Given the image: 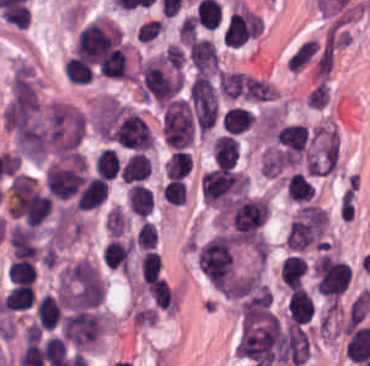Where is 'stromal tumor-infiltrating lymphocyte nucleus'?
<instances>
[{
    "label": "stromal tumor-infiltrating lymphocyte nucleus",
    "mask_w": 370,
    "mask_h": 366,
    "mask_svg": "<svg viewBox=\"0 0 370 366\" xmlns=\"http://www.w3.org/2000/svg\"><path fill=\"white\" fill-rule=\"evenodd\" d=\"M195 258L204 276H233L234 242L221 231L196 247Z\"/></svg>",
    "instance_id": "1"
},
{
    "label": "stromal tumor-infiltrating lymphocyte nucleus",
    "mask_w": 370,
    "mask_h": 366,
    "mask_svg": "<svg viewBox=\"0 0 370 366\" xmlns=\"http://www.w3.org/2000/svg\"><path fill=\"white\" fill-rule=\"evenodd\" d=\"M162 135L170 148L184 149L193 139V119L187 100L175 97L163 109Z\"/></svg>",
    "instance_id": "2"
},
{
    "label": "stromal tumor-infiltrating lymphocyte nucleus",
    "mask_w": 370,
    "mask_h": 366,
    "mask_svg": "<svg viewBox=\"0 0 370 366\" xmlns=\"http://www.w3.org/2000/svg\"><path fill=\"white\" fill-rule=\"evenodd\" d=\"M189 56L195 70L200 73H214L219 59L216 48L207 38L195 37L189 45Z\"/></svg>",
    "instance_id": "3"
},
{
    "label": "stromal tumor-infiltrating lymphocyte nucleus",
    "mask_w": 370,
    "mask_h": 366,
    "mask_svg": "<svg viewBox=\"0 0 370 366\" xmlns=\"http://www.w3.org/2000/svg\"><path fill=\"white\" fill-rule=\"evenodd\" d=\"M289 323H308L314 314L311 295L302 287H295L287 302Z\"/></svg>",
    "instance_id": "4"
},
{
    "label": "stromal tumor-infiltrating lymphocyte nucleus",
    "mask_w": 370,
    "mask_h": 366,
    "mask_svg": "<svg viewBox=\"0 0 370 366\" xmlns=\"http://www.w3.org/2000/svg\"><path fill=\"white\" fill-rule=\"evenodd\" d=\"M107 179L90 176L78 191L77 209L90 210L105 200Z\"/></svg>",
    "instance_id": "5"
},
{
    "label": "stromal tumor-infiltrating lymphocyte nucleus",
    "mask_w": 370,
    "mask_h": 366,
    "mask_svg": "<svg viewBox=\"0 0 370 366\" xmlns=\"http://www.w3.org/2000/svg\"><path fill=\"white\" fill-rule=\"evenodd\" d=\"M242 100L248 103H272L276 101L275 86L265 78L247 73Z\"/></svg>",
    "instance_id": "6"
},
{
    "label": "stromal tumor-infiltrating lymphocyte nucleus",
    "mask_w": 370,
    "mask_h": 366,
    "mask_svg": "<svg viewBox=\"0 0 370 366\" xmlns=\"http://www.w3.org/2000/svg\"><path fill=\"white\" fill-rule=\"evenodd\" d=\"M212 154L216 165H235L239 157V145L233 134H220L212 143Z\"/></svg>",
    "instance_id": "7"
},
{
    "label": "stromal tumor-infiltrating lymphocyte nucleus",
    "mask_w": 370,
    "mask_h": 366,
    "mask_svg": "<svg viewBox=\"0 0 370 366\" xmlns=\"http://www.w3.org/2000/svg\"><path fill=\"white\" fill-rule=\"evenodd\" d=\"M306 268L307 261L300 255L285 256L280 266L281 280L292 290L302 283Z\"/></svg>",
    "instance_id": "8"
},
{
    "label": "stromal tumor-infiltrating lymphocyte nucleus",
    "mask_w": 370,
    "mask_h": 366,
    "mask_svg": "<svg viewBox=\"0 0 370 366\" xmlns=\"http://www.w3.org/2000/svg\"><path fill=\"white\" fill-rule=\"evenodd\" d=\"M59 303L46 293L36 301L35 315L40 328L53 329L61 315Z\"/></svg>",
    "instance_id": "9"
},
{
    "label": "stromal tumor-infiltrating lymphocyte nucleus",
    "mask_w": 370,
    "mask_h": 366,
    "mask_svg": "<svg viewBox=\"0 0 370 366\" xmlns=\"http://www.w3.org/2000/svg\"><path fill=\"white\" fill-rule=\"evenodd\" d=\"M126 196L132 212L144 217L152 212L154 198L149 187L140 183H133L130 185Z\"/></svg>",
    "instance_id": "10"
},
{
    "label": "stromal tumor-infiltrating lymphocyte nucleus",
    "mask_w": 370,
    "mask_h": 366,
    "mask_svg": "<svg viewBox=\"0 0 370 366\" xmlns=\"http://www.w3.org/2000/svg\"><path fill=\"white\" fill-rule=\"evenodd\" d=\"M150 164L142 152H134L122 164L120 176L125 181L142 180L148 175Z\"/></svg>",
    "instance_id": "11"
},
{
    "label": "stromal tumor-infiltrating lymphocyte nucleus",
    "mask_w": 370,
    "mask_h": 366,
    "mask_svg": "<svg viewBox=\"0 0 370 366\" xmlns=\"http://www.w3.org/2000/svg\"><path fill=\"white\" fill-rule=\"evenodd\" d=\"M255 121L254 112L238 106L228 107L222 117L223 127L226 132L239 133Z\"/></svg>",
    "instance_id": "12"
},
{
    "label": "stromal tumor-infiltrating lymphocyte nucleus",
    "mask_w": 370,
    "mask_h": 366,
    "mask_svg": "<svg viewBox=\"0 0 370 366\" xmlns=\"http://www.w3.org/2000/svg\"><path fill=\"white\" fill-rule=\"evenodd\" d=\"M34 302L33 290L28 284H15L7 291L1 308L21 309L32 306Z\"/></svg>",
    "instance_id": "13"
},
{
    "label": "stromal tumor-infiltrating lymphocyte nucleus",
    "mask_w": 370,
    "mask_h": 366,
    "mask_svg": "<svg viewBox=\"0 0 370 366\" xmlns=\"http://www.w3.org/2000/svg\"><path fill=\"white\" fill-rule=\"evenodd\" d=\"M220 89L226 97L236 99L244 95L246 75L241 72L220 70L218 74Z\"/></svg>",
    "instance_id": "14"
},
{
    "label": "stromal tumor-infiltrating lymphocyte nucleus",
    "mask_w": 370,
    "mask_h": 366,
    "mask_svg": "<svg viewBox=\"0 0 370 366\" xmlns=\"http://www.w3.org/2000/svg\"><path fill=\"white\" fill-rule=\"evenodd\" d=\"M153 301L162 308L172 307L174 300L168 281L161 276H154L147 283Z\"/></svg>",
    "instance_id": "15"
},
{
    "label": "stromal tumor-infiltrating lymphocyte nucleus",
    "mask_w": 370,
    "mask_h": 366,
    "mask_svg": "<svg viewBox=\"0 0 370 366\" xmlns=\"http://www.w3.org/2000/svg\"><path fill=\"white\" fill-rule=\"evenodd\" d=\"M65 78L74 84H86L90 81L91 67L82 59L76 57L67 58L64 65Z\"/></svg>",
    "instance_id": "16"
},
{
    "label": "stromal tumor-infiltrating lymphocyte nucleus",
    "mask_w": 370,
    "mask_h": 366,
    "mask_svg": "<svg viewBox=\"0 0 370 366\" xmlns=\"http://www.w3.org/2000/svg\"><path fill=\"white\" fill-rule=\"evenodd\" d=\"M164 166L171 179L187 175L192 167L190 152L187 150H174Z\"/></svg>",
    "instance_id": "17"
},
{
    "label": "stromal tumor-infiltrating lymphocyte nucleus",
    "mask_w": 370,
    "mask_h": 366,
    "mask_svg": "<svg viewBox=\"0 0 370 366\" xmlns=\"http://www.w3.org/2000/svg\"><path fill=\"white\" fill-rule=\"evenodd\" d=\"M318 49L317 40L308 38L302 42L287 59L289 68L301 69Z\"/></svg>",
    "instance_id": "18"
},
{
    "label": "stromal tumor-infiltrating lymphocyte nucleus",
    "mask_w": 370,
    "mask_h": 366,
    "mask_svg": "<svg viewBox=\"0 0 370 366\" xmlns=\"http://www.w3.org/2000/svg\"><path fill=\"white\" fill-rule=\"evenodd\" d=\"M35 273L34 265L29 259L16 258L9 267L8 278L11 282L26 283L31 282Z\"/></svg>",
    "instance_id": "19"
},
{
    "label": "stromal tumor-infiltrating lymphocyte nucleus",
    "mask_w": 370,
    "mask_h": 366,
    "mask_svg": "<svg viewBox=\"0 0 370 366\" xmlns=\"http://www.w3.org/2000/svg\"><path fill=\"white\" fill-rule=\"evenodd\" d=\"M161 259L155 250H146L139 260V267L146 279L149 280L158 276L160 272Z\"/></svg>",
    "instance_id": "20"
},
{
    "label": "stromal tumor-infiltrating lymphocyte nucleus",
    "mask_w": 370,
    "mask_h": 366,
    "mask_svg": "<svg viewBox=\"0 0 370 366\" xmlns=\"http://www.w3.org/2000/svg\"><path fill=\"white\" fill-rule=\"evenodd\" d=\"M162 193L169 203L184 204L187 193L185 181L180 178H173L165 185Z\"/></svg>",
    "instance_id": "21"
},
{
    "label": "stromal tumor-infiltrating lymphocyte nucleus",
    "mask_w": 370,
    "mask_h": 366,
    "mask_svg": "<svg viewBox=\"0 0 370 366\" xmlns=\"http://www.w3.org/2000/svg\"><path fill=\"white\" fill-rule=\"evenodd\" d=\"M307 105L313 108H323L328 102L327 81H320L316 84L306 97Z\"/></svg>",
    "instance_id": "22"
},
{
    "label": "stromal tumor-infiltrating lymphocyte nucleus",
    "mask_w": 370,
    "mask_h": 366,
    "mask_svg": "<svg viewBox=\"0 0 370 366\" xmlns=\"http://www.w3.org/2000/svg\"><path fill=\"white\" fill-rule=\"evenodd\" d=\"M136 242L141 248H150L156 244L155 224L143 220L137 234Z\"/></svg>",
    "instance_id": "23"
},
{
    "label": "stromal tumor-infiltrating lymphocyte nucleus",
    "mask_w": 370,
    "mask_h": 366,
    "mask_svg": "<svg viewBox=\"0 0 370 366\" xmlns=\"http://www.w3.org/2000/svg\"><path fill=\"white\" fill-rule=\"evenodd\" d=\"M171 69H181L185 62V56L180 47L176 44H169L163 56Z\"/></svg>",
    "instance_id": "24"
}]
</instances>
